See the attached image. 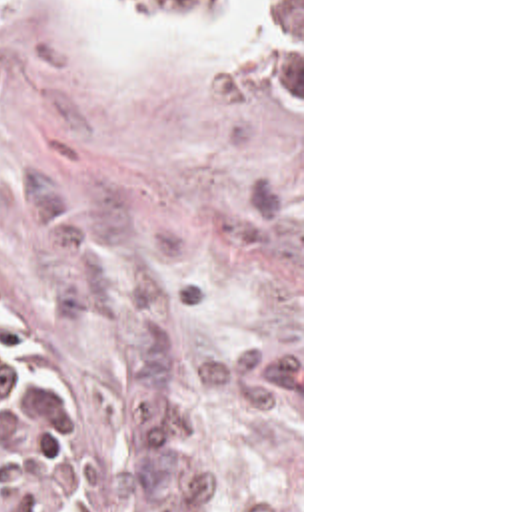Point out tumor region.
Wrapping results in <instances>:
<instances>
[{"instance_id":"obj_1","label":"tumor region","mask_w":512,"mask_h":512,"mask_svg":"<svg viewBox=\"0 0 512 512\" xmlns=\"http://www.w3.org/2000/svg\"><path fill=\"white\" fill-rule=\"evenodd\" d=\"M172 29L220 31L248 0H106ZM272 39L300 107V0H272ZM102 468L64 346L0 315V512H98Z\"/></svg>"}]
</instances>
